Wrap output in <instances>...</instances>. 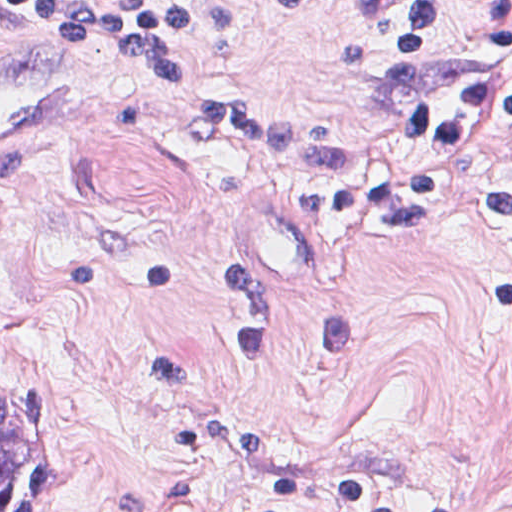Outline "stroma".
<instances>
[{
    "label": "stroma",
    "instance_id": "stroma-1",
    "mask_svg": "<svg viewBox=\"0 0 512 512\" xmlns=\"http://www.w3.org/2000/svg\"><path fill=\"white\" fill-rule=\"evenodd\" d=\"M0 1H228L212 81L376 153L391 128L337 57L353 1L512 0ZM464 156L512 172V132ZM148 342L332 465L512 512V238L324 236L299 169L199 139L146 62L25 25L0 51V358L47 394L58 512H317L201 465L148 390Z\"/></svg>",
    "mask_w": 512,
    "mask_h": 512
}]
</instances>
